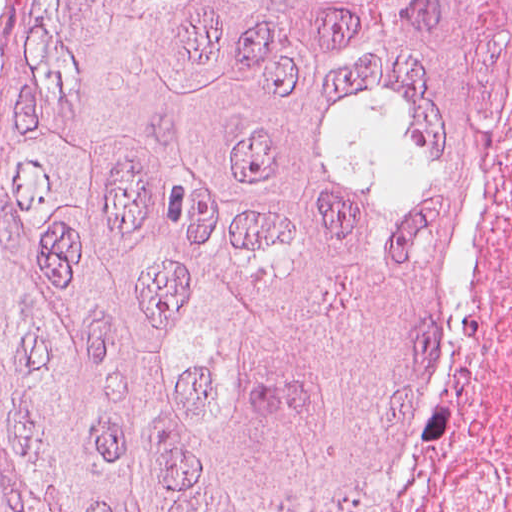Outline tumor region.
Returning <instances> with one entry per match:
<instances>
[{"label":"tumor region","instance_id":"e687c5a6","mask_svg":"<svg viewBox=\"0 0 512 512\" xmlns=\"http://www.w3.org/2000/svg\"><path fill=\"white\" fill-rule=\"evenodd\" d=\"M0 25V512H383L509 205L512 0Z\"/></svg>","mask_w":512,"mask_h":512}]
</instances>
